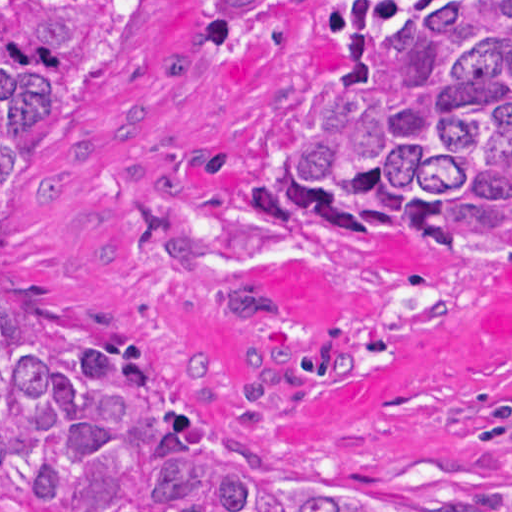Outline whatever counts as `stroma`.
<instances>
[{
	"instance_id": "stroma-1",
	"label": "stroma",
	"mask_w": 512,
	"mask_h": 512,
	"mask_svg": "<svg viewBox=\"0 0 512 512\" xmlns=\"http://www.w3.org/2000/svg\"><path fill=\"white\" fill-rule=\"evenodd\" d=\"M284 0L227 55L209 0H128L1 228V278L168 349L198 401L295 467L402 493L512 488V265L359 233L285 183L358 13Z\"/></svg>"
}]
</instances>
